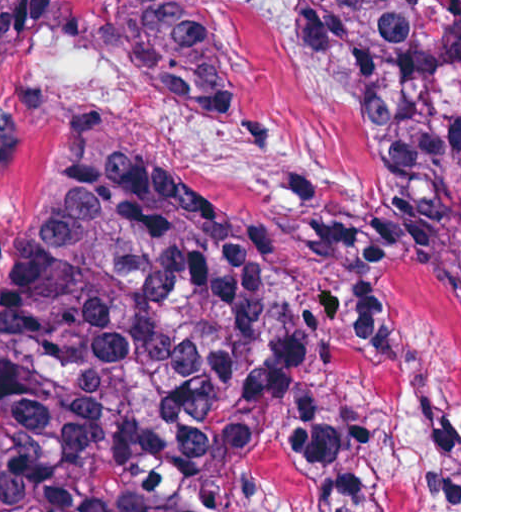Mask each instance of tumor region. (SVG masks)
<instances>
[{
	"label": "tumor region",
	"instance_id": "tumor-region-1",
	"mask_svg": "<svg viewBox=\"0 0 512 512\" xmlns=\"http://www.w3.org/2000/svg\"><path fill=\"white\" fill-rule=\"evenodd\" d=\"M313 55L378 124L387 197L307 225L346 280L299 288L289 246L181 162L77 139L0 273V512H395L329 386L412 345L401 265L459 268V0H295ZM135 83L233 133L248 121L197 0H101ZM71 0H0V91Z\"/></svg>",
	"mask_w": 512,
	"mask_h": 512
}]
</instances>
